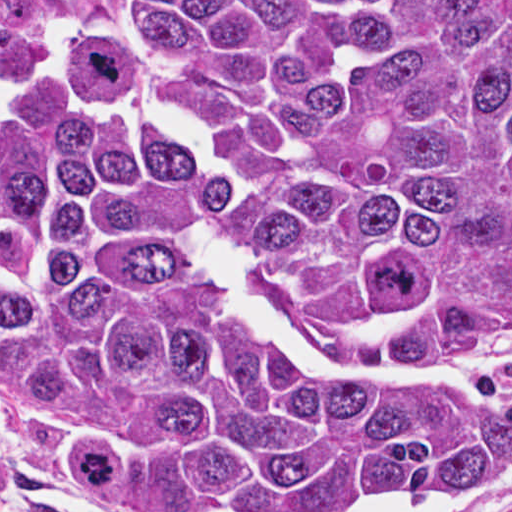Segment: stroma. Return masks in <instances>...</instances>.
<instances>
[{
    "label": "stroma",
    "instance_id": "1",
    "mask_svg": "<svg viewBox=\"0 0 512 512\" xmlns=\"http://www.w3.org/2000/svg\"><path fill=\"white\" fill-rule=\"evenodd\" d=\"M63 19L124 41V0H0V33L33 18ZM103 102L132 109L126 80ZM452 364L472 389L512 408V342L484 345L453 358H395ZM459 484V483H455ZM355 497L281 499L257 512H317ZM0 512H141L95 496L74 478L69 462L23 439L6 420L5 353L0 345ZM448 512H512V470L501 483Z\"/></svg>",
    "mask_w": 512,
    "mask_h": 512
}]
</instances>
